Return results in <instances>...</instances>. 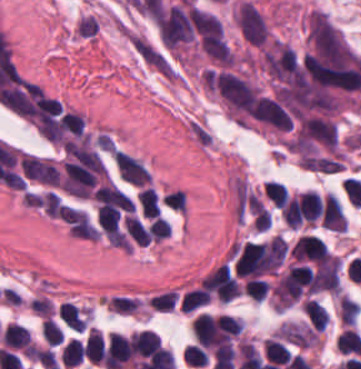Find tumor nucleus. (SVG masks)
<instances>
[{"instance_id": "1", "label": "tumor nucleus", "mask_w": 361, "mask_h": 369, "mask_svg": "<svg viewBox=\"0 0 361 369\" xmlns=\"http://www.w3.org/2000/svg\"><path fill=\"white\" fill-rule=\"evenodd\" d=\"M235 19L247 41L251 44L264 45L268 26L254 4L245 0L237 7Z\"/></svg>"}, {"instance_id": "2", "label": "tumor nucleus", "mask_w": 361, "mask_h": 369, "mask_svg": "<svg viewBox=\"0 0 361 369\" xmlns=\"http://www.w3.org/2000/svg\"><path fill=\"white\" fill-rule=\"evenodd\" d=\"M283 341L302 347L320 346L318 331L312 326L298 322H285L277 330Z\"/></svg>"}]
</instances>
